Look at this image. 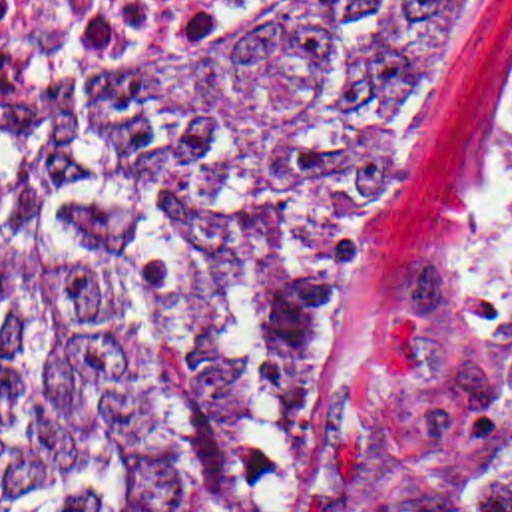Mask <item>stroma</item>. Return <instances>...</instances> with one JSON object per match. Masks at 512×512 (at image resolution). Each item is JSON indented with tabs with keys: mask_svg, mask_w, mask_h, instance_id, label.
Here are the masks:
<instances>
[{
	"mask_svg": "<svg viewBox=\"0 0 512 512\" xmlns=\"http://www.w3.org/2000/svg\"><path fill=\"white\" fill-rule=\"evenodd\" d=\"M480 1L460 0L456 47L430 77L361 221L343 238L283 342H253L199 316L153 274L68 223L0 167V177L64 231L98 246L229 356L269 372L295 398V512H363L366 466L402 410L426 396H498L512 380V13L498 37L490 83L418 300L404 320L359 346L329 350L319 338L388 187L464 73Z\"/></svg>",
	"mask_w": 512,
	"mask_h": 512,
	"instance_id": "obj_1",
	"label": "stroma"
}]
</instances>
